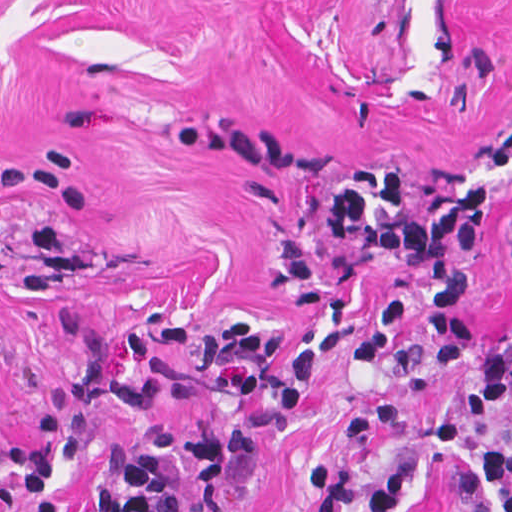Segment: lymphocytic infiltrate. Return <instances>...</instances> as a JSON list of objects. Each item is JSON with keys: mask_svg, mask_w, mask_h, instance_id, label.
<instances>
[{"mask_svg": "<svg viewBox=\"0 0 512 512\" xmlns=\"http://www.w3.org/2000/svg\"><path fill=\"white\" fill-rule=\"evenodd\" d=\"M498 168L512 165V123L492 132ZM494 195L479 181L428 212L412 203V180L402 164L377 163L335 197L332 223L343 242L362 241L397 266L413 268L403 286L377 293L344 353L343 368L365 369L403 341L407 320H419L421 349L445 377L470 378L478 410H500L512 399V325L496 340L470 313L467 280L486 246ZM179 351L202 350L213 371L236 370L240 407L212 422L183 428L152 425L137 434L73 431V406L60 396L41 400L26 439L9 455L28 512H58L53 491L83 454L101 458L106 480L93 512H178L168 473L183 463L191 492L221 512L218 481L228 461L255 459L266 423L276 413L297 414L324 380V359L314 352L275 355L272 327L254 319L222 330L171 320L159 332ZM481 484L512 512V451L479 448ZM317 512H413L415 459H396L372 474L347 463L311 468Z\"/></svg>", "mask_w": 512, "mask_h": 512, "instance_id": "1", "label": "lymphocytic infiltrate"}]
</instances>
